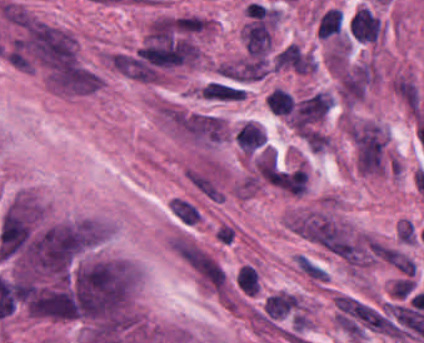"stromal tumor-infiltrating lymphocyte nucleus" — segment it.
<instances>
[{
    "mask_svg": "<svg viewBox=\"0 0 424 343\" xmlns=\"http://www.w3.org/2000/svg\"><path fill=\"white\" fill-rule=\"evenodd\" d=\"M350 30L359 41H372L380 32V20L369 7L363 6L355 11Z\"/></svg>",
    "mask_w": 424,
    "mask_h": 343,
    "instance_id": "obj_1",
    "label": "stromal tumor-infiltrating lymphocyte nucleus"
},
{
    "mask_svg": "<svg viewBox=\"0 0 424 343\" xmlns=\"http://www.w3.org/2000/svg\"><path fill=\"white\" fill-rule=\"evenodd\" d=\"M342 29V13L339 7H331L319 20L318 31L323 37L340 33Z\"/></svg>",
    "mask_w": 424,
    "mask_h": 343,
    "instance_id": "obj_2",
    "label": "stromal tumor-infiltrating lymphocyte nucleus"
},
{
    "mask_svg": "<svg viewBox=\"0 0 424 343\" xmlns=\"http://www.w3.org/2000/svg\"><path fill=\"white\" fill-rule=\"evenodd\" d=\"M270 109L279 113L287 114L294 102L289 90L282 86H275L269 99Z\"/></svg>",
    "mask_w": 424,
    "mask_h": 343,
    "instance_id": "obj_3",
    "label": "stromal tumor-infiltrating lymphocyte nucleus"
},
{
    "mask_svg": "<svg viewBox=\"0 0 424 343\" xmlns=\"http://www.w3.org/2000/svg\"><path fill=\"white\" fill-rule=\"evenodd\" d=\"M236 281L247 293H254L259 285V277L255 267L250 264H242L236 273Z\"/></svg>",
    "mask_w": 424,
    "mask_h": 343,
    "instance_id": "obj_4",
    "label": "stromal tumor-infiltrating lymphocyte nucleus"
}]
</instances>
